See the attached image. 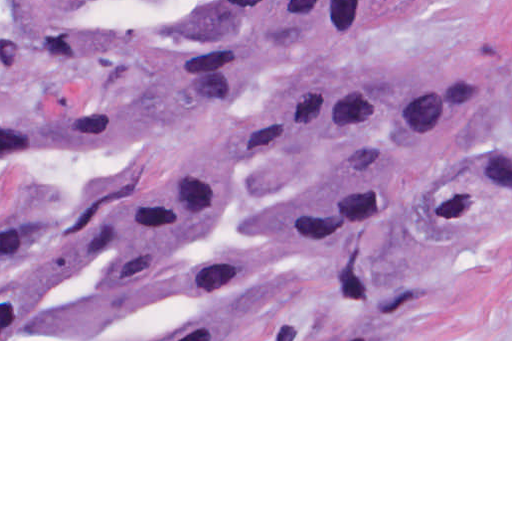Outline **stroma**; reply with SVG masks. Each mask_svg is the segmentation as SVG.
<instances>
[{"mask_svg": "<svg viewBox=\"0 0 512 512\" xmlns=\"http://www.w3.org/2000/svg\"><path fill=\"white\" fill-rule=\"evenodd\" d=\"M100 80L0 57V124L82 102ZM338 92L495 98V119L512 127V0H401L358 40L291 56L229 106L131 150L0 162V263L103 251L162 149L217 134L209 125L236 142L295 102ZM384 176L410 189L384 203L348 255L289 259L269 240L306 192L371 187ZM174 261L313 281L408 279L414 298L383 339L0 341H512V162H239V199Z\"/></svg>", "mask_w": 512, "mask_h": 512, "instance_id": "obj_1", "label": "stroma"}]
</instances>
